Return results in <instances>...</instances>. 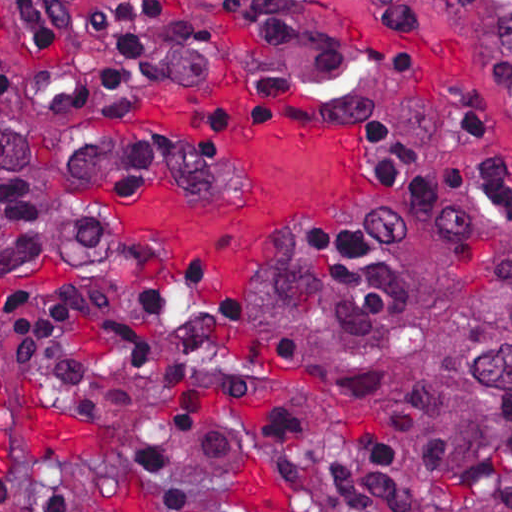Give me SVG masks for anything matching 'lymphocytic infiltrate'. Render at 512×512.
Masks as SVG:
<instances>
[{
  "label": "lymphocytic infiltrate",
  "instance_id": "1",
  "mask_svg": "<svg viewBox=\"0 0 512 512\" xmlns=\"http://www.w3.org/2000/svg\"><path fill=\"white\" fill-rule=\"evenodd\" d=\"M51 76L71 94H120L144 85L192 45L170 12L169 0H11ZM398 34L418 24L413 0H369ZM410 38V37H409ZM411 39V38H410ZM413 40V39H411ZM369 169L386 190L422 199H461L512 206V164L410 138L383 123L362 125ZM140 316L159 313L163 294L182 306L173 318L189 336L190 357L164 363L149 339L118 321L107 339L133 356L139 377L161 397L179 428L202 426L239 406L266 423L280 468L284 501L278 508L235 506L196 480L166 453L132 448L130 465L142 484L172 512H333L331 486L304 436L249 354L201 318L167 274L149 271L106 291ZM0 512H102L72 475H0Z\"/></svg>",
  "mask_w": 512,
  "mask_h": 512
}]
</instances>
